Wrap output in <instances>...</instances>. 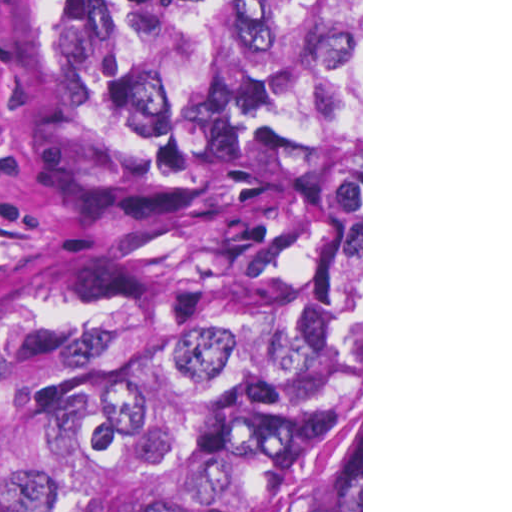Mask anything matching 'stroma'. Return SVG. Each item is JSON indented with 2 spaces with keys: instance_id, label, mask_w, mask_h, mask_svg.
Returning <instances> with one entry per match:
<instances>
[{
  "instance_id": "1",
  "label": "stroma",
  "mask_w": 512,
  "mask_h": 512,
  "mask_svg": "<svg viewBox=\"0 0 512 512\" xmlns=\"http://www.w3.org/2000/svg\"><path fill=\"white\" fill-rule=\"evenodd\" d=\"M12 3L0 0V264L85 241H125L222 213L133 207L64 168L25 119L12 59ZM361 512H363V0H361Z\"/></svg>"
}]
</instances>
